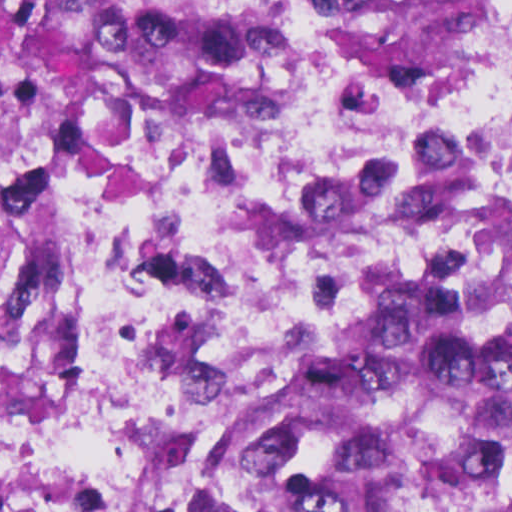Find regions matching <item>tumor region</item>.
Masks as SVG:
<instances>
[{
	"instance_id": "1",
	"label": "tumor region",
	"mask_w": 512,
	"mask_h": 512,
	"mask_svg": "<svg viewBox=\"0 0 512 512\" xmlns=\"http://www.w3.org/2000/svg\"><path fill=\"white\" fill-rule=\"evenodd\" d=\"M32 67L28 232L9 325L53 450L87 459L35 391L50 175L86 106L268 71L265 0H0ZM362 84L409 94L512 44V0H340ZM512 190L391 269L238 336L198 371L156 476L108 472L117 512H512ZM88 460V459H87Z\"/></svg>"
}]
</instances>
